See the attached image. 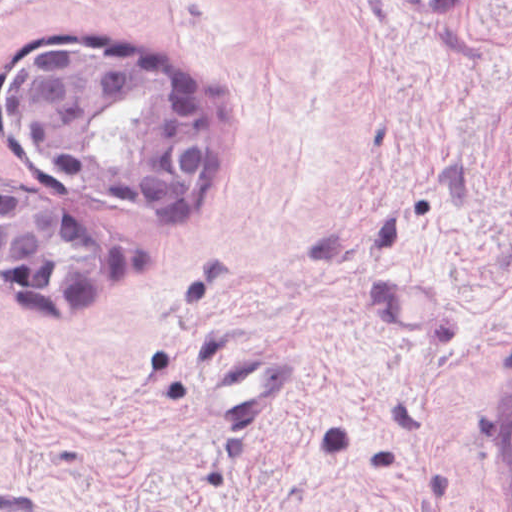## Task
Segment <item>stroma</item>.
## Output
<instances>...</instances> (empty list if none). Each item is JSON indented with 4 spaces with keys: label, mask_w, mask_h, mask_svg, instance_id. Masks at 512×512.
Masks as SVG:
<instances>
[{
    "label": "stroma",
    "mask_w": 512,
    "mask_h": 512,
    "mask_svg": "<svg viewBox=\"0 0 512 512\" xmlns=\"http://www.w3.org/2000/svg\"><path fill=\"white\" fill-rule=\"evenodd\" d=\"M55 29L204 82L205 188L141 199L16 136L5 66ZM0 183L139 239L90 310L0 293V495L512 512V0H0ZM283 345L282 417L220 420L219 363Z\"/></svg>",
    "instance_id": "obj_1"
}]
</instances>
